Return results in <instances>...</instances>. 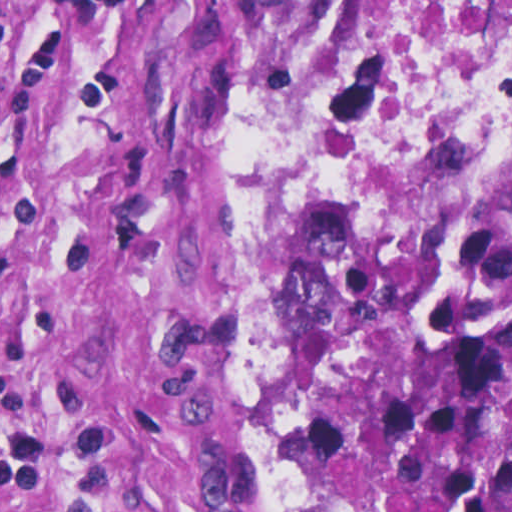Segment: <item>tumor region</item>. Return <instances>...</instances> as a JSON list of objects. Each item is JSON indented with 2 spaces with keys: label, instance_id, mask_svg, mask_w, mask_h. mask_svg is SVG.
I'll return each instance as SVG.
<instances>
[{
  "label": "tumor region",
  "instance_id": "e687c5a6",
  "mask_svg": "<svg viewBox=\"0 0 512 512\" xmlns=\"http://www.w3.org/2000/svg\"><path fill=\"white\" fill-rule=\"evenodd\" d=\"M293 34L302 273L256 361L258 512H512V135L329 141Z\"/></svg>",
  "mask_w": 512,
  "mask_h": 512
}]
</instances>
